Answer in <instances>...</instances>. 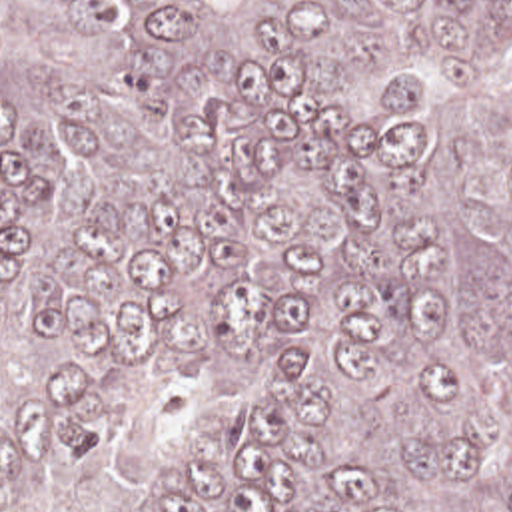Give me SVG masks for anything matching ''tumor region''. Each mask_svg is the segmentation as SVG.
Wrapping results in <instances>:
<instances>
[{
  "label": "tumor region",
  "instance_id": "1",
  "mask_svg": "<svg viewBox=\"0 0 512 512\" xmlns=\"http://www.w3.org/2000/svg\"><path fill=\"white\" fill-rule=\"evenodd\" d=\"M0 512H512V0H0Z\"/></svg>",
  "mask_w": 512,
  "mask_h": 512
}]
</instances>
